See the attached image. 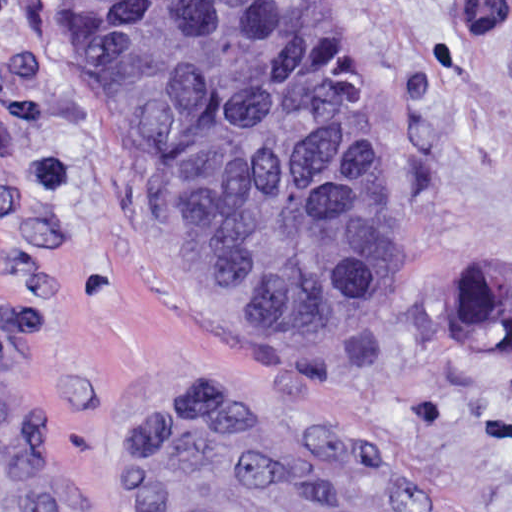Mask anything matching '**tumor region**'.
<instances>
[{
    "label": "tumor region",
    "instance_id": "1",
    "mask_svg": "<svg viewBox=\"0 0 512 512\" xmlns=\"http://www.w3.org/2000/svg\"><path fill=\"white\" fill-rule=\"evenodd\" d=\"M78 94L119 187L141 201L206 310L260 338L388 320L417 291L364 124L344 30L324 0H62ZM506 0H454L477 55ZM512 286L482 258L447 285L451 333L512 358Z\"/></svg>",
    "mask_w": 512,
    "mask_h": 512
}]
</instances>
